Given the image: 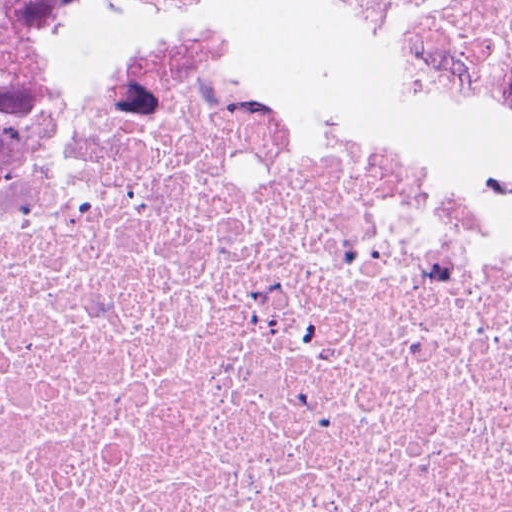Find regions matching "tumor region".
Masks as SVG:
<instances>
[{"mask_svg":"<svg viewBox=\"0 0 512 512\" xmlns=\"http://www.w3.org/2000/svg\"><path fill=\"white\" fill-rule=\"evenodd\" d=\"M470 48L512 95V0H369Z\"/></svg>","mask_w":512,"mask_h":512,"instance_id":"obj_1","label":"tumor region"}]
</instances>
